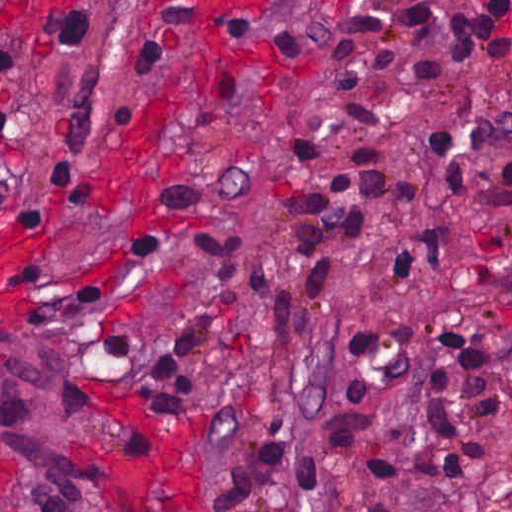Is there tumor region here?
Listing matches in <instances>:
<instances>
[{"instance_id":"1","label":"tumor region","mask_w":512,"mask_h":512,"mask_svg":"<svg viewBox=\"0 0 512 512\" xmlns=\"http://www.w3.org/2000/svg\"><path fill=\"white\" fill-rule=\"evenodd\" d=\"M61 366L54 340L0 323V440L22 477L78 502L70 466L78 411L58 403Z\"/></svg>"}]
</instances>
